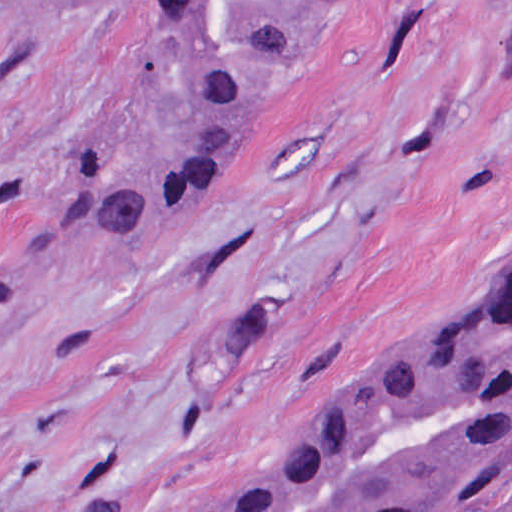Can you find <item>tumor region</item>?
Here are the masks:
<instances>
[{
  "label": "tumor region",
  "instance_id": "tumor-region-1",
  "mask_svg": "<svg viewBox=\"0 0 512 512\" xmlns=\"http://www.w3.org/2000/svg\"><path fill=\"white\" fill-rule=\"evenodd\" d=\"M79 7L99 0H59ZM160 91L144 149L81 144L0 197V307L188 224L329 0H117ZM501 69L512 71V0ZM512 490V277L304 411L209 512H485Z\"/></svg>",
  "mask_w": 512,
  "mask_h": 512
}]
</instances>
